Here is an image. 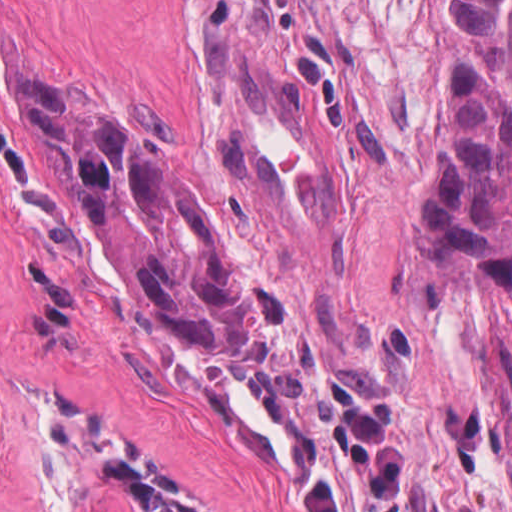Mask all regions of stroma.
<instances>
[{
	"label": "stroma",
	"instance_id": "obj_1",
	"mask_svg": "<svg viewBox=\"0 0 512 512\" xmlns=\"http://www.w3.org/2000/svg\"><path fill=\"white\" fill-rule=\"evenodd\" d=\"M455 0H0V343L98 512L133 454L197 512H300L304 475L364 512L314 393L394 409L403 512H512V288L432 241L424 185ZM211 41L311 78L344 155L334 232L279 241L233 179ZM27 78L188 168L241 261L255 359H205L104 274Z\"/></svg>",
	"mask_w": 512,
	"mask_h": 512
}]
</instances>
